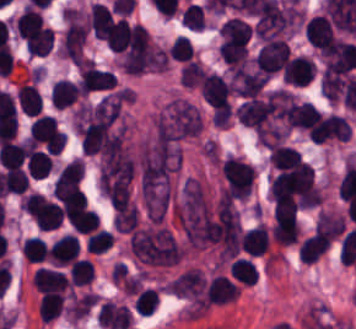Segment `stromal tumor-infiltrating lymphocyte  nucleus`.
Wrapping results in <instances>:
<instances>
[{
  "mask_svg": "<svg viewBox=\"0 0 356 329\" xmlns=\"http://www.w3.org/2000/svg\"><path fill=\"white\" fill-rule=\"evenodd\" d=\"M314 65L309 55H290L281 68V78L285 85L303 87L313 76Z\"/></svg>",
  "mask_w": 356,
  "mask_h": 329,
  "instance_id": "1",
  "label": "stromal tumor-infiltrating lymphocyte nucleus"
},
{
  "mask_svg": "<svg viewBox=\"0 0 356 329\" xmlns=\"http://www.w3.org/2000/svg\"><path fill=\"white\" fill-rule=\"evenodd\" d=\"M305 33L310 45L324 54L335 39L329 19L322 14H314L305 21Z\"/></svg>",
  "mask_w": 356,
  "mask_h": 329,
  "instance_id": "2",
  "label": "stromal tumor-infiltrating lymphocyte nucleus"
},
{
  "mask_svg": "<svg viewBox=\"0 0 356 329\" xmlns=\"http://www.w3.org/2000/svg\"><path fill=\"white\" fill-rule=\"evenodd\" d=\"M32 286L38 291H64L70 286L66 275L55 268L38 267L31 276Z\"/></svg>",
  "mask_w": 356,
  "mask_h": 329,
  "instance_id": "3",
  "label": "stromal tumor-infiltrating lymphocyte nucleus"
},
{
  "mask_svg": "<svg viewBox=\"0 0 356 329\" xmlns=\"http://www.w3.org/2000/svg\"><path fill=\"white\" fill-rule=\"evenodd\" d=\"M205 290L212 304H223L238 296L239 287L227 275L216 273L209 279Z\"/></svg>",
  "mask_w": 356,
  "mask_h": 329,
  "instance_id": "4",
  "label": "stromal tumor-infiltrating lymphocyte nucleus"
},
{
  "mask_svg": "<svg viewBox=\"0 0 356 329\" xmlns=\"http://www.w3.org/2000/svg\"><path fill=\"white\" fill-rule=\"evenodd\" d=\"M15 95L19 108L26 115H35L42 109V96L34 81L22 80Z\"/></svg>",
  "mask_w": 356,
  "mask_h": 329,
  "instance_id": "5",
  "label": "stromal tumor-infiltrating lymphocyte nucleus"
},
{
  "mask_svg": "<svg viewBox=\"0 0 356 329\" xmlns=\"http://www.w3.org/2000/svg\"><path fill=\"white\" fill-rule=\"evenodd\" d=\"M76 83L67 77H60L53 82L49 91V102L58 107L70 106L80 95Z\"/></svg>",
  "mask_w": 356,
  "mask_h": 329,
  "instance_id": "6",
  "label": "stromal tumor-infiltrating lymphocyte nucleus"
},
{
  "mask_svg": "<svg viewBox=\"0 0 356 329\" xmlns=\"http://www.w3.org/2000/svg\"><path fill=\"white\" fill-rule=\"evenodd\" d=\"M329 244L325 236L312 233L298 243V260L312 264Z\"/></svg>",
  "mask_w": 356,
  "mask_h": 329,
  "instance_id": "7",
  "label": "stromal tumor-infiltrating lymphocyte nucleus"
},
{
  "mask_svg": "<svg viewBox=\"0 0 356 329\" xmlns=\"http://www.w3.org/2000/svg\"><path fill=\"white\" fill-rule=\"evenodd\" d=\"M64 299L61 292L43 291L37 304L38 317L42 322H50L58 317Z\"/></svg>",
  "mask_w": 356,
  "mask_h": 329,
  "instance_id": "8",
  "label": "stromal tumor-infiltrating lymphocyte nucleus"
},
{
  "mask_svg": "<svg viewBox=\"0 0 356 329\" xmlns=\"http://www.w3.org/2000/svg\"><path fill=\"white\" fill-rule=\"evenodd\" d=\"M66 220L72 231L79 233H89L99 225L96 210L85 206L66 215Z\"/></svg>",
  "mask_w": 356,
  "mask_h": 329,
  "instance_id": "9",
  "label": "stromal tumor-infiltrating lymphocyte nucleus"
},
{
  "mask_svg": "<svg viewBox=\"0 0 356 329\" xmlns=\"http://www.w3.org/2000/svg\"><path fill=\"white\" fill-rule=\"evenodd\" d=\"M53 159L45 150L34 148L30 151L26 161V171L31 178H43L50 173Z\"/></svg>",
  "mask_w": 356,
  "mask_h": 329,
  "instance_id": "10",
  "label": "stromal tumor-infiltrating lymphocyte nucleus"
},
{
  "mask_svg": "<svg viewBox=\"0 0 356 329\" xmlns=\"http://www.w3.org/2000/svg\"><path fill=\"white\" fill-rule=\"evenodd\" d=\"M258 269L249 258L237 257L230 265L228 273L243 285H254Z\"/></svg>",
  "mask_w": 356,
  "mask_h": 329,
  "instance_id": "11",
  "label": "stromal tumor-infiltrating lymphocyte nucleus"
},
{
  "mask_svg": "<svg viewBox=\"0 0 356 329\" xmlns=\"http://www.w3.org/2000/svg\"><path fill=\"white\" fill-rule=\"evenodd\" d=\"M300 158L298 150L283 144L271 146L268 154L269 164L276 167H291L299 162Z\"/></svg>",
  "mask_w": 356,
  "mask_h": 329,
  "instance_id": "12",
  "label": "stromal tumor-infiltrating lymphocyte nucleus"
},
{
  "mask_svg": "<svg viewBox=\"0 0 356 329\" xmlns=\"http://www.w3.org/2000/svg\"><path fill=\"white\" fill-rule=\"evenodd\" d=\"M20 251L27 263L45 259L46 245L40 236H27L20 242Z\"/></svg>",
  "mask_w": 356,
  "mask_h": 329,
  "instance_id": "13",
  "label": "stromal tumor-infiltrating lymphocyte nucleus"
},
{
  "mask_svg": "<svg viewBox=\"0 0 356 329\" xmlns=\"http://www.w3.org/2000/svg\"><path fill=\"white\" fill-rule=\"evenodd\" d=\"M93 263L85 257L72 260L69 271L70 285H89Z\"/></svg>",
  "mask_w": 356,
  "mask_h": 329,
  "instance_id": "14",
  "label": "stromal tumor-infiltrating lymphocyte nucleus"
},
{
  "mask_svg": "<svg viewBox=\"0 0 356 329\" xmlns=\"http://www.w3.org/2000/svg\"><path fill=\"white\" fill-rule=\"evenodd\" d=\"M158 303V291L151 287H144L134 298L135 311L141 315H151Z\"/></svg>",
  "mask_w": 356,
  "mask_h": 329,
  "instance_id": "15",
  "label": "stromal tumor-infiltrating lymphocyte nucleus"
},
{
  "mask_svg": "<svg viewBox=\"0 0 356 329\" xmlns=\"http://www.w3.org/2000/svg\"><path fill=\"white\" fill-rule=\"evenodd\" d=\"M167 53L173 59L182 63L193 59L194 56L193 47L189 39L179 35L175 37L171 44L168 46Z\"/></svg>",
  "mask_w": 356,
  "mask_h": 329,
  "instance_id": "16",
  "label": "stromal tumor-infiltrating lymphocyte nucleus"
}]
</instances>
